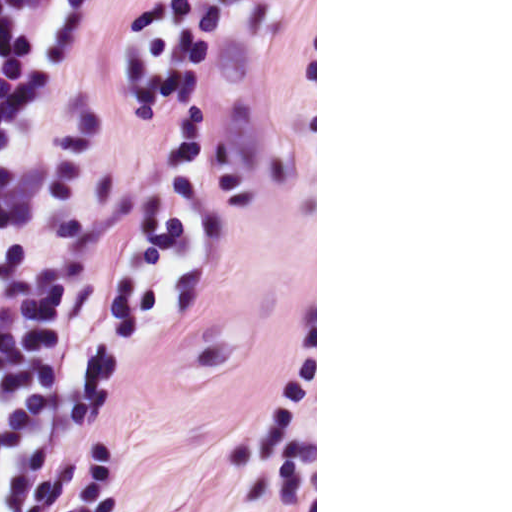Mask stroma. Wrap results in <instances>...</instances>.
Masks as SVG:
<instances>
[{"mask_svg":"<svg viewBox=\"0 0 512 512\" xmlns=\"http://www.w3.org/2000/svg\"><path fill=\"white\" fill-rule=\"evenodd\" d=\"M110 326L41 512H181L317 451L118 0L87 17Z\"/></svg>","mask_w":512,"mask_h":512,"instance_id":"1","label":"stroma"}]
</instances>
